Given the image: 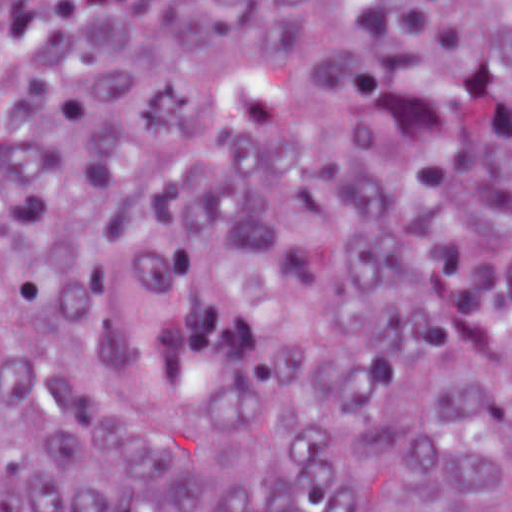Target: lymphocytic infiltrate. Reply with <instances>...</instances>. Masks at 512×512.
Masks as SVG:
<instances>
[{
	"mask_svg": "<svg viewBox=\"0 0 512 512\" xmlns=\"http://www.w3.org/2000/svg\"><path fill=\"white\" fill-rule=\"evenodd\" d=\"M119 0H0V134L29 85L49 74Z\"/></svg>",
	"mask_w": 512,
	"mask_h": 512,
	"instance_id": "1",
	"label": "lymphocytic infiltrate"
}]
</instances>
